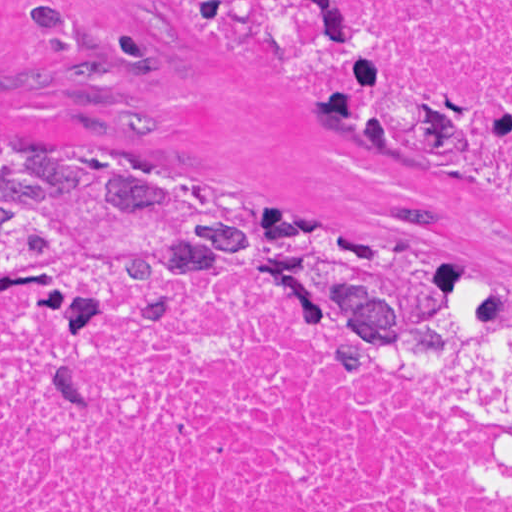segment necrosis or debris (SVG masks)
I'll use <instances>...</instances> for the list:
<instances>
[{
	"label": "necrosis or debris",
	"instance_id": "necrosis-or-debris-1",
	"mask_svg": "<svg viewBox=\"0 0 512 512\" xmlns=\"http://www.w3.org/2000/svg\"><path fill=\"white\" fill-rule=\"evenodd\" d=\"M512 113V0H365ZM464 178L512 207L501 158ZM0 512H512V311L288 255L0 285Z\"/></svg>",
	"mask_w": 512,
	"mask_h": 512
}]
</instances>
